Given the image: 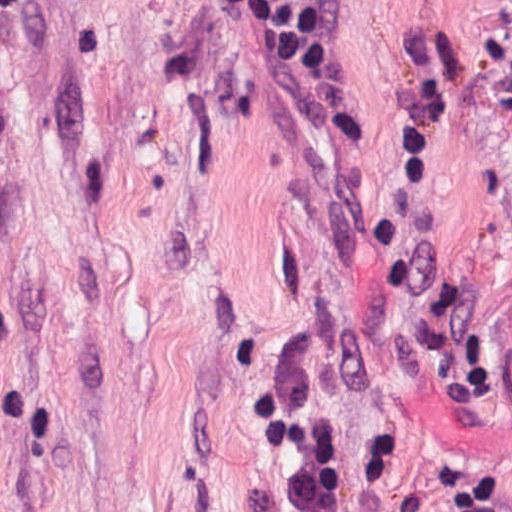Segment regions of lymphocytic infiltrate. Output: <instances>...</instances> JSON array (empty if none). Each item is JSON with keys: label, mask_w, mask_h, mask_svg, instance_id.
Instances as JSON below:
<instances>
[{"label": "lymphocytic infiltrate", "mask_w": 512, "mask_h": 512, "mask_svg": "<svg viewBox=\"0 0 512 512\" xmlns=\"http://www.w3.org/2000/svg\"><path fill=\"white\" fill-rule=\"evenodd\" d=\"M342 0H231L262 57L302 94L321 93L334 60ZM268 399L258 427L265 447L290 464V512H341L338 447L317 395L288 363L261 366L252 382ZM281 385L283 403L272 400Z\"/></svg>", "instance_id": "lymphocytic-infiltrate-1"}]
</instances>
